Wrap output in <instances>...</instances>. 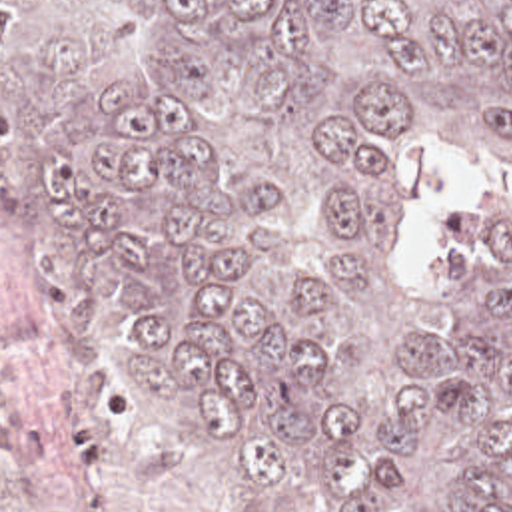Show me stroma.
I'll return each instance as SVG.
<instances>
[{
	"instance_id": "35a3bbf8",
	"label": "stroma",
	"mask_w": 512,
	"mask_h": 512,
	"mask_svg": "<svg viewBox=\"0 0 512 512\" xmlns=\"http://www.w3.org/2000/svg\"><path fill=\"white\" fill-rule=\"evenodd\" d=\"M40 317L52 353L20 374L18 418L48 452L0 468V512H339L319 498L273 502L204 458L176 416L132 380L122 345H100L72 305V283L32 259L12 229V143L0 103V321Z\"/></svg>"
}]
</instances>
